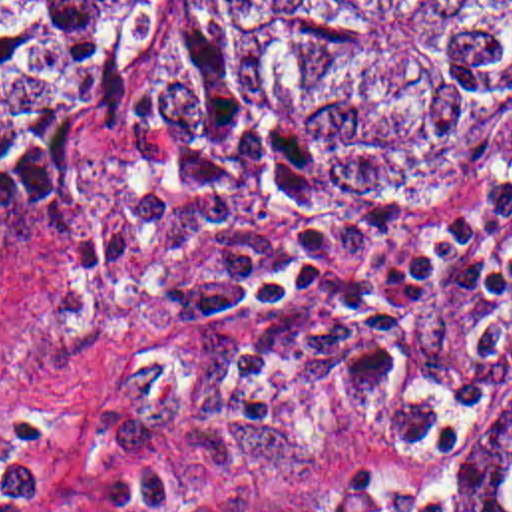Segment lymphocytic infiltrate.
<instances>
[{
    "instance_id": "1",
    "label": "lymphocytic infiltrate",
    "mask_w": 512,
    "mask_h": 512,
    "mask_svg": "<svg viewBox=\"0 0 512 512\" xmlns=\"http://www.w3.org/2000/svg\"><path fill=\"white\" fill-rule=\"evenodd\" d=\"M512 199V171L493 177L443 219L399 263L349 281L343 273L403 219L385 215L361 223L276 235H246L196 322L210 328L300 301L331 303L345 324L351 392H385L415 382L409 322L431 271L461 257ZM41 466L33 452L0 460V512H35Z\"/></svg>"
}]
</instances>
